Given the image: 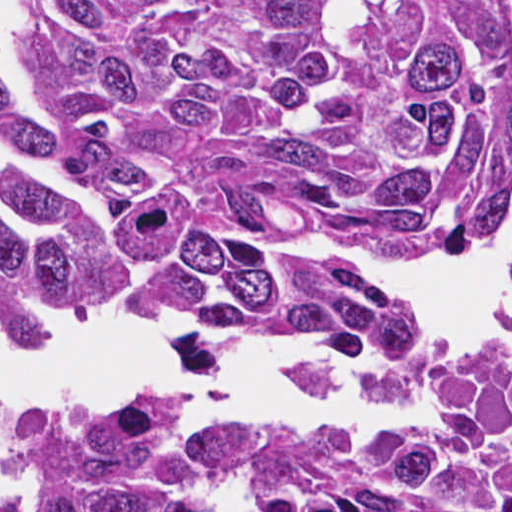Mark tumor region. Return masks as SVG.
<instances>
[{
	"label": "tumor region",
	"mask_w": 512,
	"mask_h": 512,
	"mask_svg": "<svg viewBox=\"0 0 512 512\" xmlns=\"http://www.w3.org/2000/svg\"><path fill=\"white\" fill-rule=\"evenodd\" d=\"M43 120L0 66V156L102 196L142 308L229 337L297 331L392 351L400 298L265 237L423 240L496 224L512 176V52L481 0H30ZM35 238L0 225V314L101 300L98 255L50 175L0 169ZM512 280V253L509 262ZM363 396L423 401L417 444L226 431L207 452L267 512H512V380L457 346ZM30 512H195L169 399L0 425Z\"/></svg>",
	"instance_id": "e687c5a6"
}]
</instances>
